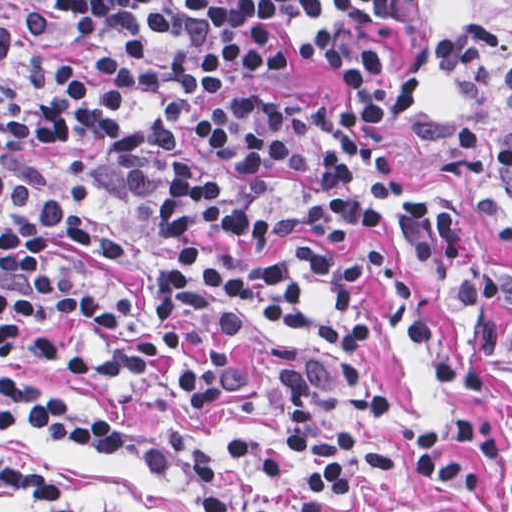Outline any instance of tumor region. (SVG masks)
I'll list each match as a JSON object with an SVG mask.
<instances>
[{
	"instance_id": "e687c5a6",
	"label": "tumor region",
	"mask_w": 512,
	"mask_h": 512,
	"mask_svg": "<svg viewBox=\"0 0 512 512\" xmlns=\"http://www.w3.org/2000/svg\"><path fill=\"white\" fill-rule=\"evenodd\" d=\"M448 4L476 16L493 28L512 35V0H446Z\"/></svg>"
}]
</instances>
